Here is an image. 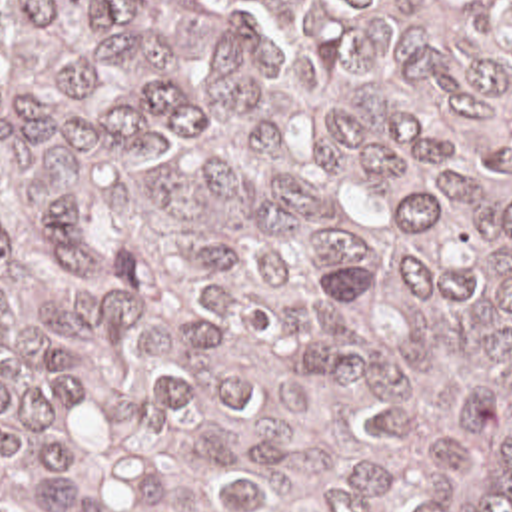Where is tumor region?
Returning a JSON list of instances; mask_svg holds the SVG:
<instances>
[{
	"instance_id": "tumor-region-1",
	"label": "tumor region",
	"mask_w": 512,
	"mask_h": 512,
	"mask_svg": "<svg viewBox=\"0 0 512 512\" xmlns=\"http://www.w3.org/2000/svg\"><path fill=\"white\" fill-rule=\"evenodd\" d=\"M0 512H512V0H0Z\"/></svg>"
}]
</instances>
